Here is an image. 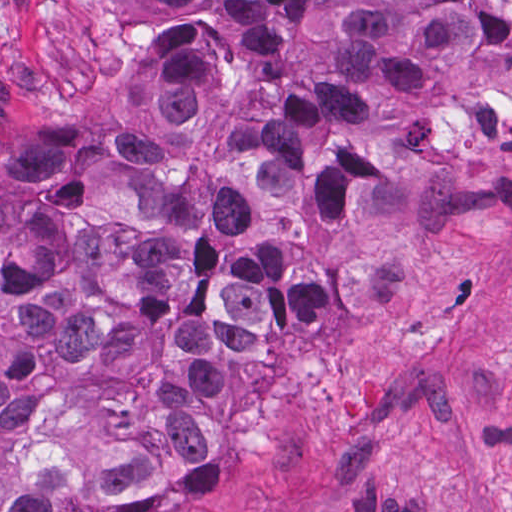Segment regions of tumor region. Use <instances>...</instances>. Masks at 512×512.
<instances>
[{"mask_svg":"<svg viewBox=\"0 0 512 512\" xmlns=\"http://www.w3.org/2000/svg\"><path fill=\"white\" fill-rule=\"evenodd\" d=\"M136 125L0 126V512L220 501L227 358L314 355L457 232L512 0H133Z\"/></svg>","mask_w":512,"mask_h":512,"instance_id":"tumor-region-1","label":"tumor region"}]
</instances>
